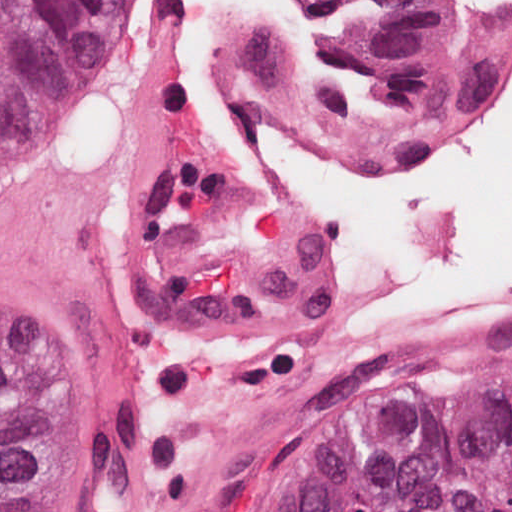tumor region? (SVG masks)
Wrapping results in <instances>:
<instances>
[{
    "label": "tumor region",
    "mask_w": 512,
    "mask_h": 512,
    "mask_svg": "<svg viewBox=\"0 0 512 512\" xmlns=\"http://www.w3.org/2000/svg\"><path fill=\"white\" fill-rule=\"evenodd\" d=\"M401 129L469 116L498 90L504 19L437 0H307ZM135 0H0V187L79 115ZM50 403L42 375L0 342V512H46ZM268 512H512V378L435 380L313 462Z\"/></svg>",
    "instance_id": "e687c5a6"
}]
</instances>
